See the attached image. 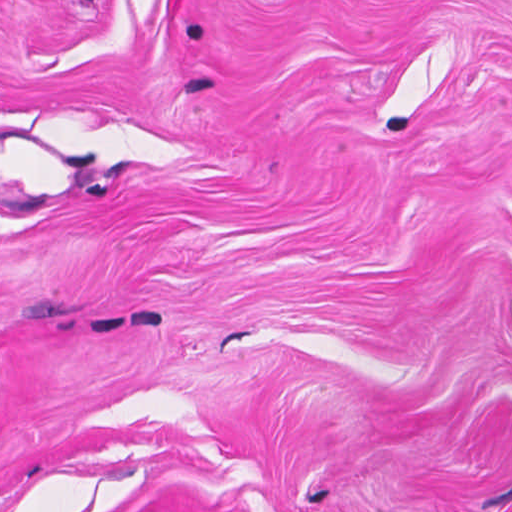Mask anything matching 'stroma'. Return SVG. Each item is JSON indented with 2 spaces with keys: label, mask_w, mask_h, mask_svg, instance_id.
<instances>
[{
  "label": "stroma",
  "mask_w": 512,
  "mask_h": 512,
  "mask_svg": "<svg viewBox=\"0 0 512 512\" xmlns=\"http://www.w3.org/2000/svg\"><path fill=\"white\" fill-rule=\"evenodd\" d=\"M0 512H512V0H0Z\"/></svg>",
  "instance_id": "1"
}]
</instances>
